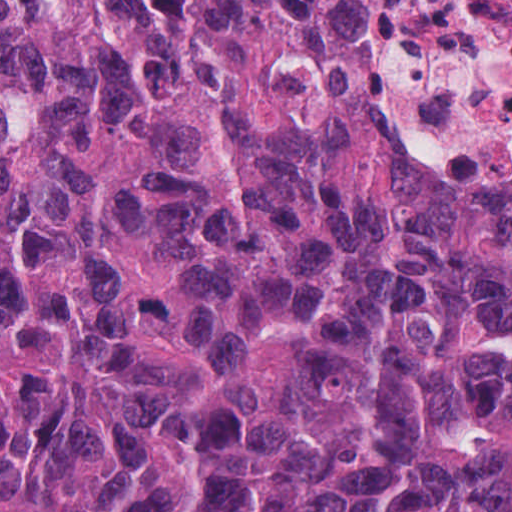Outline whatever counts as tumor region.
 Wrapping results in <instances>:
<instances>
[{"instance_id":"obj_1","label":"tumor region","mask_w":512,"mask_h":512,"mask_svg":"<svg viewBox=\"0 0 512 512\" xmlns=\"http://www.w3.org/2000/svg\"><path fill=\"white\" fill-rule=\"evenodd\" d=\"M396 0H0V512H512V184L383 126Z\"/></svg>"}]
</instances>
